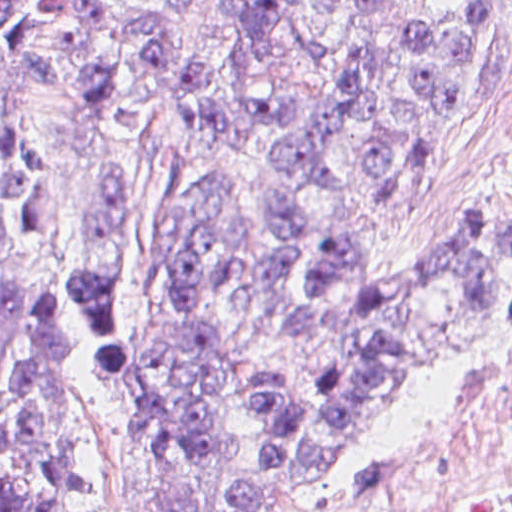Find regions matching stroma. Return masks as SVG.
<instances>
[{
  "label": "stroma",
  "instance_id": "1",
  "mask_svg": "<svg viewBox=\"0 0 512 512\" xmlns=\"http://www.w3.org/2000/svg\"><path fill=\"white\" fill-rule=\"evenodd\" d=\"M227 2L194 0L175 22V54L152 95L153 130L95 137L59 100L45 96L33 101L37 87L23 70L0 68V130L20 133L50 164L49 220L9 264L0 252V304L57 305L41 297L64 290L80 273L89 187L104 164L122 167L108 274L117 332L125 342L158 345L216 337L224 376L221 451L213 469L190 485V501L212 507L254 483L265 451L263 415L250 385L258 378L287 375L303 394L309 379L301 354L293 341L232 294L204 300L181 324L168 321L159 277V226L166 201L161 145L172 149L174 141L173 83L181 65L212 59L214 99L226 111L229 125L225 134L195 152L192 169L196 174L212 167L232 177L258 253H278L292 263L283 285L288 304L316 300L304 280L305 266L349 232L366 253L371 284L456 235L467 222L496 250L485 338L423 366L412 391L381 428L369 470L352 488L307 511L380 512L449 415L512 366V259L502 232L487 226L512 209V0H479L493 32L489 53L422 143L415 189L400 199L372 202L402 177L409 126L389 116L394 167L380 183L363 180L358 169L361 126L333 151L336 168L348 173L346 186L315 191L318 215L295 245L280 243L271 231L270 191L288 177L263 154L245 109L263 98H324L327 80L315 63L285 48L251 66L246 42L226 15ZM459 6L460 0L382 2L374 68L386 93L402 89V52L414 27L449 19ZM298 28L307 39L328 46L334 70L343 75L353 60L351 18L326 13L322 0H307ZM62 308L83 343V440L100 512H160L134 466L116 402L112 358L85 318Z\"/></svg>",
  "mask_w": 512,
  "mask_h": 512
}]
</instances>
